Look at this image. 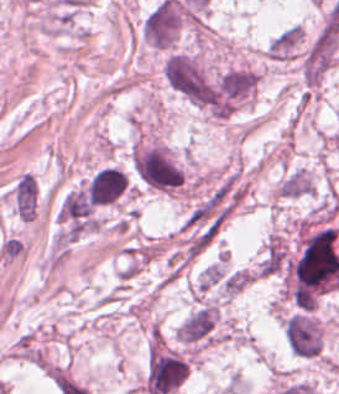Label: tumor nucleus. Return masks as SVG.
<instances>
[{
	"label": "tumor nucleus",
	"mask_w": 339,
	"mask_h": 394,
	"mask_svg": "<svg viewBox=\"0 0 339 394\" xmlns=\"http://www.w3.org/2000/svg\"><path fill=\"white\" fill-rule=\"evenodd\" d=\"M288 349L296 356L319 357L324 349L322 320L309 310H296L282 317Z\"/></svg>",
	"instance_id": "tumor-nucleus-1"
},
{
	"label": "tumor nucleus",
	"mask_w": 339,
	"mask_h": 394,
	"mask_svg": "<svg viewBox=\"0 0 339 394\" xmlns=\"http://www.w3.org/2000/svg\"><path fill=\"white\" fill-rule=\"evenodd\" d=\"M82 181L99 207L121 204L128 193V175L116 164L104 163Z\"/></svg>",
	"instance_id": "tumor-nucleus-2"
}]
</instances>
